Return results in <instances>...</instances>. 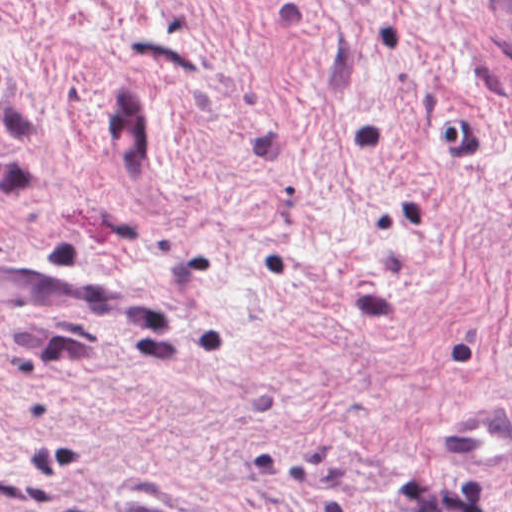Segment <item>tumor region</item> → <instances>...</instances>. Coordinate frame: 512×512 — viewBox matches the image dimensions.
<instances>
[{
	"label": "tumor region",
	"mask_w": 512,
	"mask_h": 512,
	"mask_svg": "<svg viewBox=\"0 0 512 512\" xmlns=\"http://www.w3.org/2000/svg\"><path fill=\"white\" fill-rule=\"evenodd\" d=\"M491 20L502 41L512 48V1H489Z\"/></svg>",
	"instance_id": "e687c5a6"
}]
</instances>
